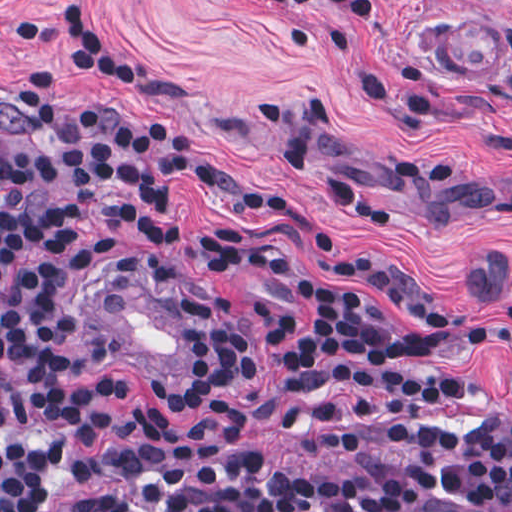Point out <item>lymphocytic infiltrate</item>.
I'll use <instances>...</instances> for the list:
<instances>
[{"instance_id": "f902f5d3", "label": "lymphocytic infiltrate", "mask_w": 512, "mask_h": 512, "mask_svg": "<svg viewBox=\"0 0 512 512\" xmlns=\"http://www.w3.org/2000/svg\"><path fill=\"white\" fill-rule=\"evenodd\" d=\"M7 111L25 119V147L0 143V298L51 318L80 372L106 441L122 465L124 512H512V415L489 407L461 377L393 369L462 350L512 356V310L464 317L377 269L336 254L344 274L373 284L440 321L423 330L320 285L279 236L213 229L208 252L222 265L287 290L305 326L261 303L277 346L271 405L291 414L320 389H366L329 405L320 441L327 459L310 471L277 474L254 446L246 406L219 401L196 425L170 428L150 408L129 404L110 382L123 359L97 336L86 301L117 269H166L182 285L195 364L187 380L157 392L190 409L254 368L237 294L218 292L189 262L164 254L102 261L88 269L81 306H64L80 258L73 228L102 219V235H145L171 243L179 217L173 188L194 176L223 201L240 180L161 165L132 154L60 107L39 64ZM367 214L332 190H318ZM29 442L0 448V512L50 510L73 493L88 466V435L42 414L11 390L0 358V436Z\"/></svg>"}]
</instances>
